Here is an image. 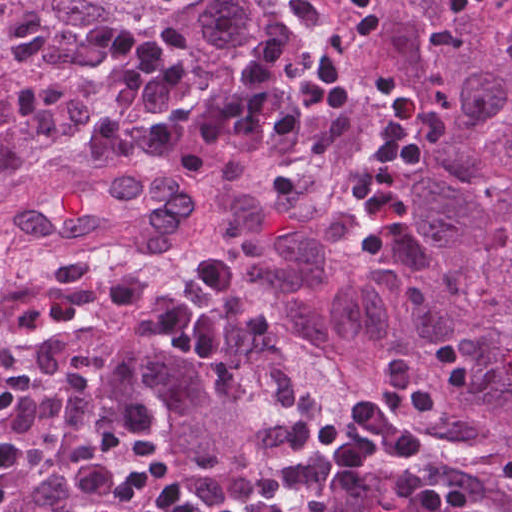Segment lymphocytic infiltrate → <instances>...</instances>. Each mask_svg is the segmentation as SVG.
I'll list each match as a JSON object with an SVG mask.
<instances>
[{"instance_id": "obj_1", "label": "lymphocytic infiltrate", "mask_w": 512, "mask_h": 512, "mask_svg": "<svg viewBox=\"0 0 512 512\" xmlns=\"http://www.w3.org/2000/svg\"><path fill=\"white\" fill-rule=\"evenodd\" d=\"M482 6L512 14V0H449L446 11ZM381 24L379 4L351 0L293 82L275 85L289 46L262 43L237 74L231 95L187 106L192 76L169 36L121 17L99 18L86 46L115 75V89L81 124L76 166L117 180L152 160L186 179L212 180L223 156L281 151L315 114L355 98L359 58ZM422 165L416 139L379 132L352 176L354 215L365 225L401 224L411 207L401 176ZM446 403L435 382L388 356L373 390L346 411L319 416L295 443L321 468L341 473L397 461L408 512H473L468 488L423 456L420 422L441 418Z\"/></svg>"}]
</instances>
